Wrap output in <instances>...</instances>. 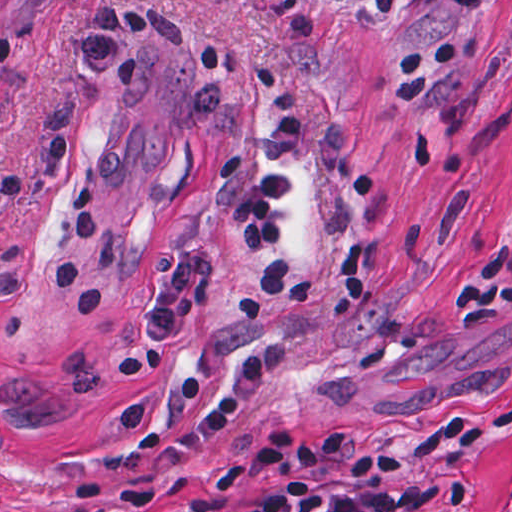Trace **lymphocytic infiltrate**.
I'll return each mask as SVG.
<instances>
[{"label":"lymphocytic infiltrate","mask_w":512,"mask_h":512,"mask_svg":"<svg viewBox=\"0 0 512 512\" xmlns=\"http://www.w3.org/2000/svg\"><path fill=\"white\" fill-rule=\"evenodd\" d=\"M465 46L443 43L404 55L401 101H417L433 86L431 67L458 63ZM249 72L273 110L262 142L263 169L227 206V217L248 257L263 265L226 298L240 320H256L275 299L297 306L313 297L345 315L368 298L362 279L361 245L339 256L338 268L349 283L318 286L287 259L289 239L278 215L293 180L284 171L298 139L309 127V104L286 70L271 60L249 64ZM268 372L263 353L236 363L194 432L199 443L219 440L233 418L262 386ZM234 475L249 479L254 493L224 502L221 512H422L448 500L458 489L454 470L418 459H397L370 431L316 437H255L228 459Z\"/></svg>","instance_id":"lymphocytic-infiltrate-1"}]
</instances>
